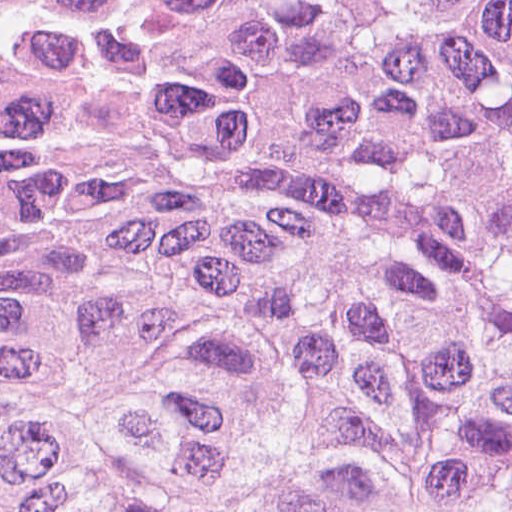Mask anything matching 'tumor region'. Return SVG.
I'll list each match as a JSON object with an SVG mask.
<instances>
[{
	"instance_id": "tumor-region-1",
	"label": "tumor region",
	"mask_w": 512,
	"mask_h": 512,
	"mask_svg": "<svg viewBox=\"0 0 512 512\" xmlns=\"http://www.w3.org/2000/svg\"><path fill=\"white\" fill-rule=\"evenodd\" d=\"M0 512H512V0H0Z\"/></svg>"
}]
</instances>
